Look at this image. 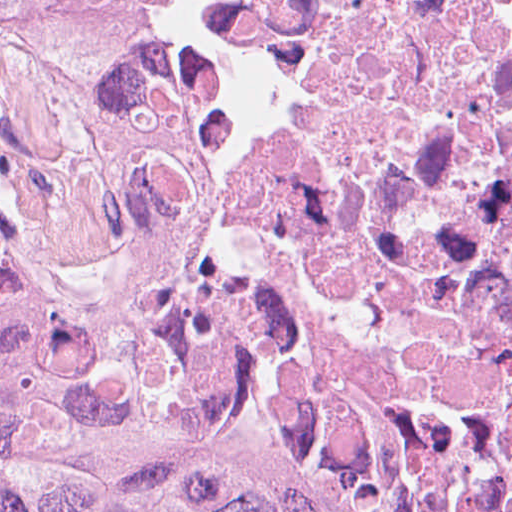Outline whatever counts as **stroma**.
Instances as JSON below:
<instances>
[{
    "mask_svg": "<svg viewBox=\"0 0 512 512\" xmlns=\"http://www.w3.org/2000/svg\"><path fill=\"white\" fill-rule=\"evenodd\" d=\"M205 327L242 356L261 404L288 449L336 473L379 486H445L512 504V477L426 457L365 437L282 430L271 415L267 396L239 340L223 329Z\"/></svg>",
    "mask_w": 512,
    "mask_h": 512,
    "instance_id": "1",
    "label": "stroma"
}]
</instances>
